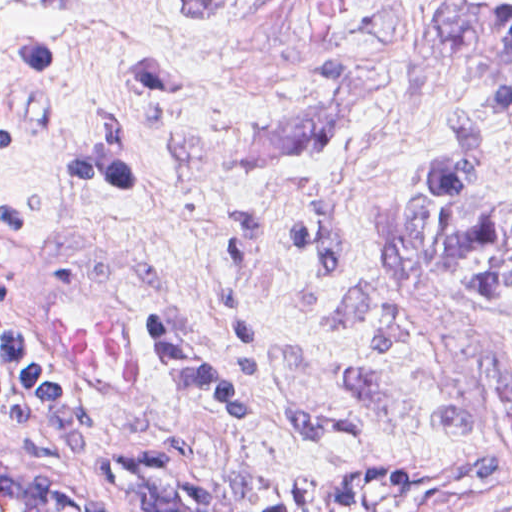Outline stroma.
I'll list each match as a JSON object with an SVG mask.
<instances>
[{
	"label": "stroma",
	"instance_id": "35a3bbf8",
	"mask_svg": "<svg viewBox=\"0 0 512 512\" xmlns=\"http://www.w3.org/2000/svg\"><path fill=\"white\" fill-rule=\"evenodd\" d=\"M427 1L0 0V123L18 143L0 197L39 217L0 231L1 297L38 346L39 273L82 272L152 380L149 402L119 410L51 362L95 435L59 447L0 414V448L120 512H512V300L423 270L406 233L435 151L411 98ZM7 30L66 66L22 72ZM96 131L127 198L58 166ZM474 208L512 220V98ZM244 216L261 220L243 285L259 384L236 429L144 322L171 316L239 377L218 276Z\"/></svg>",
	"mask_w": 512,
	"mask_h": 512
}]
</instances>
